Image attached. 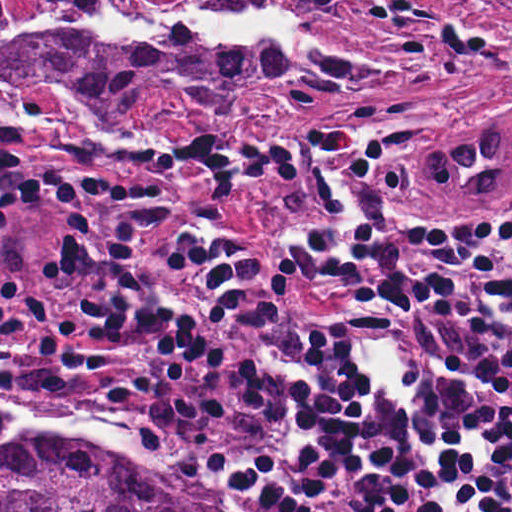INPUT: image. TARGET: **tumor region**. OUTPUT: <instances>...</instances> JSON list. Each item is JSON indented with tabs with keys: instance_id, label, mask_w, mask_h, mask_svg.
<instances>
[{
	"instance_id": "1",
	"label": "tumor region",
	"mask_w": 512,
	"mask_h": 512,
	"mask_svg": "<svg viewBox=\"0 0 512 512\" xmlns=\"http://www.w3.org/2000/svg\"><path fill=\"white\" fill-rule=\"evenodd\" d=\"M383 0H206L229 12L284 9L297 15L288 54L242 45L206 48L177 30L100 40L73 35L7 36L36 9L83 24L107 0H1V99L13 83L52 74L98 110L182 109L194 119H247L320 90L394 72L313 30L322 10L371 8ZM183 8L175 5H157ZM400 171L438 198L484 218L512 204V106L453 121L433 160ZM12 422L1 408V429ZM1 512H194L186 492L113 444L75 431L1 440Z\"/></svg>"
}]
</instances>
